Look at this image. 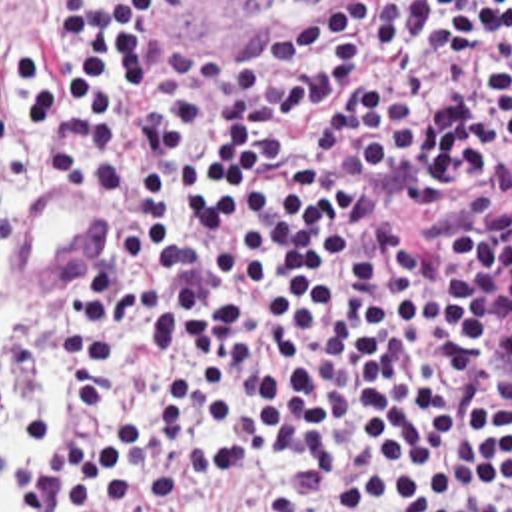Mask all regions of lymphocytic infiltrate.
I'll list each match as a JSON object with an SVG mask.
<instances>
[{
    "instance_id": "lymphocytic-infiltrate-1",
    "label": "lymphocytic infiltrate",
    "mask_w": 512,
    "mask_h": 512,
    "mask_svg": "<svg viewBox=\"0 0 512 512\" xmlns=\"http://www.w3.org/2000/svg\"><path fill=\"white\" fill-rule=\"evenodd\" d=\"M0 92L113 198L77 394L11 422L21 512H512V0H47ZM209 475L280 493L181 503Z\"/></svg>"
}]
</instances>
